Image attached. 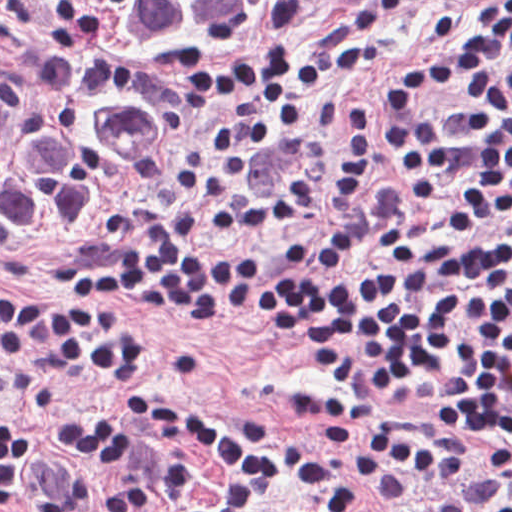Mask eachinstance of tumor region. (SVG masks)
Here are the masks:
<instances>
[{
    "instance_id": "obj_1",
    "label": "tumor region",
    "mask_w": 512,
    "mask_h": 512,
    "mask_svg": "<svg viewBox=\"0 0 512 512\" xmlns=\"http://www.w3.org/2000/svg\"><path fill=\"white\" fill-rule=\"evenodd\" d=\"M274 0H0V252H45L145 169Z\"/></svg>"
}]
</instances>
